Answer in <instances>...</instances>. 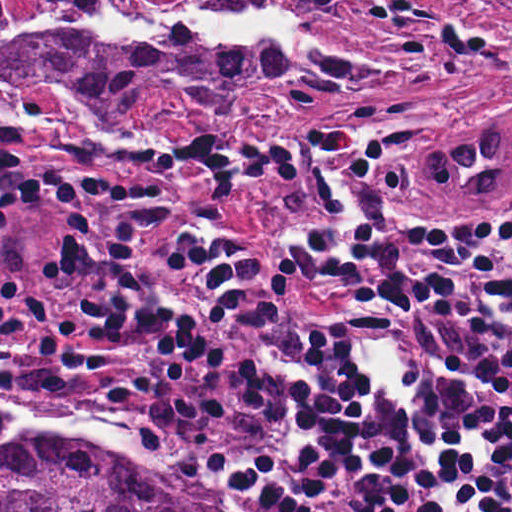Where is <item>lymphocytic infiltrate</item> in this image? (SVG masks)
<instances>
[{
	"mask_svg": "<svg viewBox=\"0 0 512 512\" xmlns=\"http://www.w3.org/2000/svg\"><path fill=\"white\" fill-rule=\"evenodd\" d=\"M1 118V398L132 427L166 447L212 512H512V232L444 218L354 129L245 150L197 125L185 164L211 197L291 185L319 209L284 237L282 264L348 300L301 313L252 241L208 224L170 251L200 277L193 312L139 278L166 192L55 168L59 259L76 314L27 281L7 219L34 203ZM82 160L160 165L155 146L97 138ZM352 343L397 344L419 387L400 408L345 365Z\"/></svg>",
	"mask_w": 512,
	"mask_h": 512,
	"instance_id": "1",
	"label": "lymphocytic infiltrate"
}]
</instances>
